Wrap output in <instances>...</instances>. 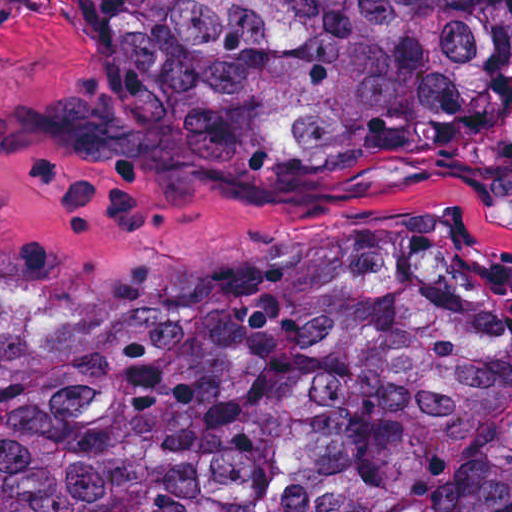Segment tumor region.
Here are the masks:
<instances>
[{
  "mask_svg": "<svg viewBox=\"0 0 512 512\" xmlns=\"http://www.w3.org/2000/svg\"><path fill=\"white\" fill-rule=\"evenodd\" d=\"M217 152L512 155V0H148ZM0 512H512V294L456 226L138 315L0 297Z\"/></svg>",
  "mask_w": 512,
  "mask_h": 512,
  "instance_id": "e687c5a6",
  "label": "tumor region"
}]
</instances>
